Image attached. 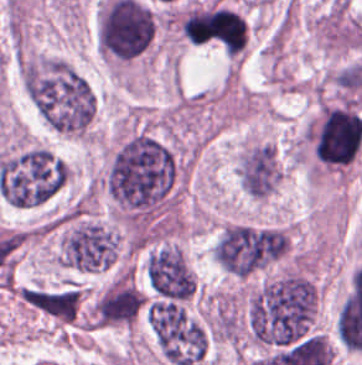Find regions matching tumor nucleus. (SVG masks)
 <instances>
[{
    "label": "tumor nucleus",
    "instance_id": "1",
    "mask_svg": "<svg viewBox=\"0 0 362 365\" xmlns=\"http://www.w3.org/2000/svg\"><path fill=\"white\" fill-rule=\"evenodd\" d=\"M234 172L239 189L263 203L279 190L285 166L275 142L258 134H244L235 159Z\"/></svg>",
    "mask_w": 362,
    "mask_h": 365
},
{
    "label": "tumor nucleus",
    "instance_id": "2",
    "mask_svg": "<svg viewBox=\"0 0 362 365\" xmlns=\"http://www.w3.org/2000/svg\"><path fill=\"white\" fill-rule=\"evenodd\" d=\"M146 284L161 297L189 301L196 290L193 271L180 245H154L145 251Z\"/></svg>",
    "mask_w": 362,
    "mask_h": 365
}]
</instances>
